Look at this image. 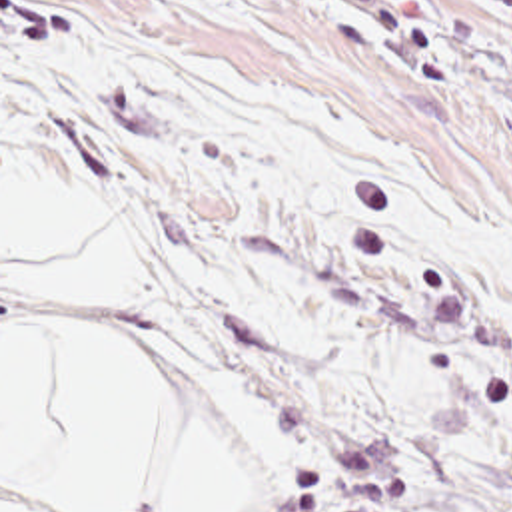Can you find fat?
<instances>
[{
    "instance_id": "1",
    "label": "fat",
    "mask_w": 512,
    "mask_h": 512,
    "mask_svg": "<svg viewBox=\"0 0 512 512\" xmlns=\"http://www.w3.org/2000/svg\"><path fill=\"white\" fill-rule=\"evenodd\" d=\"M136 512H232L246 489L166 373L118 338Z\"/></svg>"
}]
</instances>
